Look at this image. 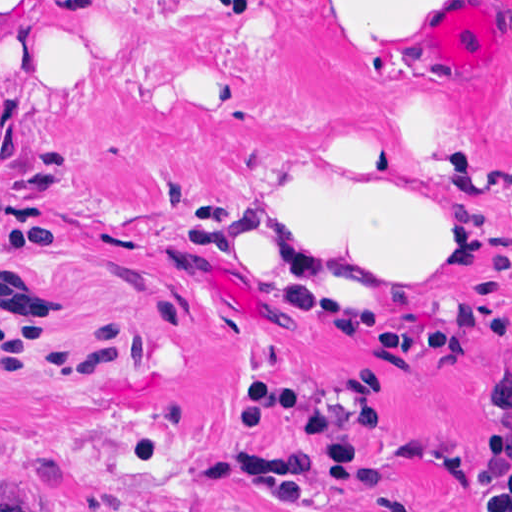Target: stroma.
<instances>
[{"label":"stroma","instance_id":"1","mask_svg":"<svg viewBox=\"0 0 512 512\" xmlns=\"http://www.w3.org/2000/svg\"><path fill=\"white\" fill-rule=\"evenodd\" d=\"M137 34L82 87L0 101V512H482L484 421L512 350L395 364L379 319L512 308V0H437L430 62L363 66L316 0H40ZM298 176L403 184L473 239L450 261L334 301L225 274L243 226ZM171 235V238L169 237ZM252 385L367 423L377 489L307 508L204 482L284 456L308 426L246 424Z\"/></svg>","mask_w":512,"mask_h":512}]
</instances>
